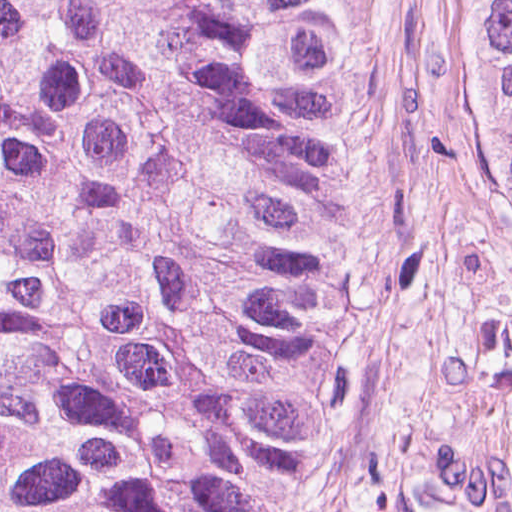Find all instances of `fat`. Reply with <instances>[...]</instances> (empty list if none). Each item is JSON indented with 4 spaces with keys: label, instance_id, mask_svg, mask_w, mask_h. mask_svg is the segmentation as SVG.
<instances>
[{
    "label": "fat",
    "instance_id": "1",
    "mask_svg": "<svg viewBox=\"0 0 512 512\" xmlns=\"http://www.w3.org/2000/svg\"><path fill=\"white\" fill-rule=\"evenodd\" d=\"M418 512H512V502L466 479L447 482Z\"/></svg>",
    "mask_w": 512,
    "mask_h": 512
}]
</instances>
